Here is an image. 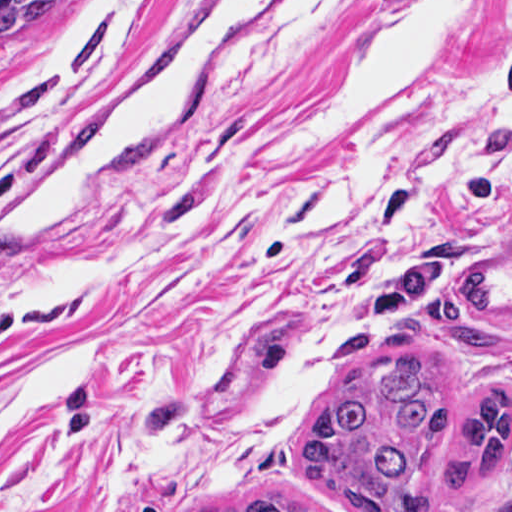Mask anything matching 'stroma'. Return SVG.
I'll use <instances>...</instances> for the list:
<instances>
[{
	"mask_svg": "<svg viewBox=\"0 0 512 512\" xmlns=\"http://www.w3.org/2000/svg\"><path fill=\"white\" fill-rule=\"evenodd\" d=\"M190 0H86L53 40L0 53V217L72 130L128 96ZM422 0H278L245 52L140 159L127 191L0 250V512H200L324 494L300 456L331 392L413 354L461 413L509 387L504 477L436 511L512 512V210L471 215L512 165L500 47L512 0H481L371 114L259 161L346 52ZM483 267L496 350L419 328L415 307Z\"/></svg>",
	"mask_w": 512,
	"mask_h": 512,
	"instance_id": "1",
	"label": "stroma"
}]
</instances>
